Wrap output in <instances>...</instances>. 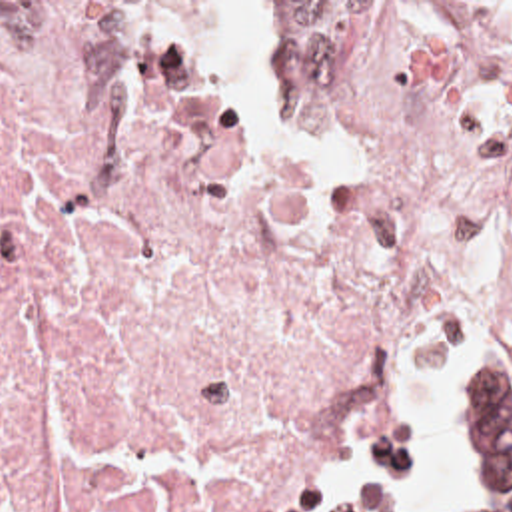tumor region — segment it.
<instances>
[{
	"label": "tumor region",
	"mask_w": 512,
	"mask_h": 512,
	"mask_svg": "<svg viewBox=\"0 0 512 512\" xmlns=\"http://www.w3.org/2000/svg\"><path fill=\"white\" fill-rule=\"evenodd\" d=\"M459 475L471 512H512V345H495L459 383Z\"/></svg>",
	"instance_id": "e687c5a6"
}]
</instances>
